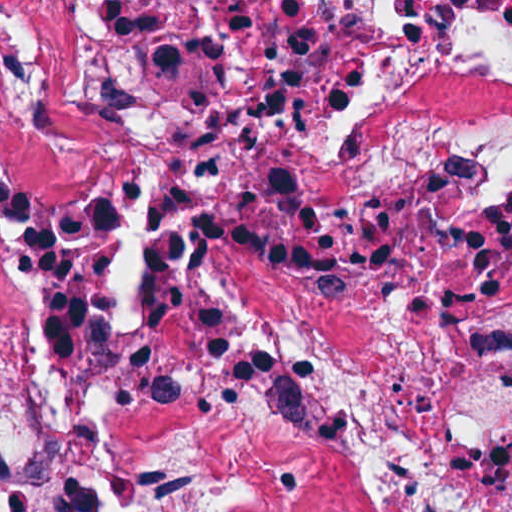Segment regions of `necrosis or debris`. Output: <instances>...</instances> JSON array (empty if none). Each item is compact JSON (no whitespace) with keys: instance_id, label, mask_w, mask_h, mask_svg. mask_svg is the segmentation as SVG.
Listing matches in <instances>:
<instances>
[{"instance_id":"4bbe7bcc","label":"necrosis or debris","mask_w":512,"mask_h":512,"mask_svg":"<svg viewBox=\"0 0 512 512\" xmlns=\"http://www.w3.org/2000/svg\"><path fill=\"white\" fill-rule=\"evenodd\" d=\"M0 512H512V1H0Z\"/></svg>"}]
</instances>
